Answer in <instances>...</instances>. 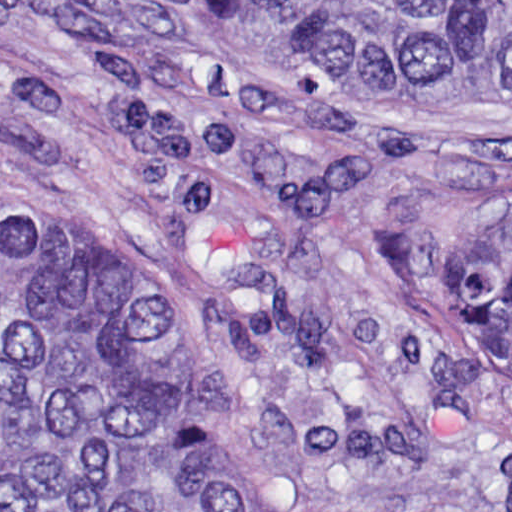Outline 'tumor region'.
<instances>
[{
  "label": "tumor region",
  "instance_id": "e687c5a6",
  "mask_svg": "<svg viewBox=\"0 0 512 512\" xmlns=\"http://www.w3.org/2000/svg\"><path fill=\"white\" fill-rule=\"evenodd\" d=\"M300 33L328 83L403 114H512V0H213ZM468 314L512 383V220L471 232ZM0 512H267L143 289L0 223Z\"/></svg>",
  "mask_w": 512,
  "mask_h": 512
}]
</instances>
